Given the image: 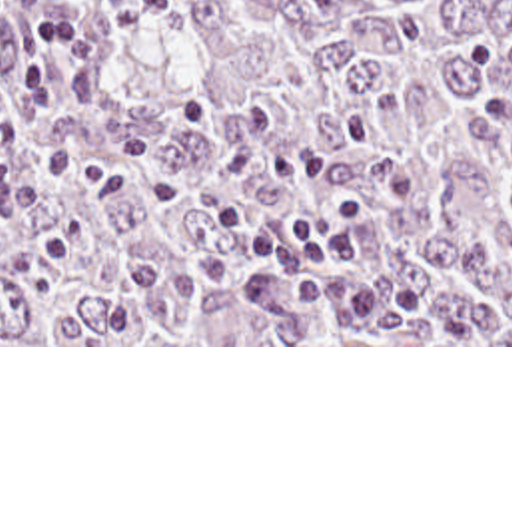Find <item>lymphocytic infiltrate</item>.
<instances>
[{"mask_svg":"<svg viewBox=\"0 0 512 512\" xmlns=\"http://www.w3.org/2000/svg\"><path fill=\"white\" fill-rule=\"evenodd\" d=\"M89 57L91 42L77 28V0H55L31 18L19 52V83L11 91H0V151H17L23 143L21 131L11 127L17 109L53 107L55 65H81ZM371 213V201L353 195L303 209L281 223L233 205L219 209L223 229L253 247L263 263L243 275L239 289L249 299H265L303 279L293 291L303 311L341 313L355 325H389L433 313L435 299L415 285L335 275L321 265L329 259L355 261L359 243L341 229L365 221Z\"/></svg>","mask_w":512,"mask_h":512,"instance_id":"lymphocytic-infiltrate-1","label":"lymphocytic infiltrate"}]
</instances>
